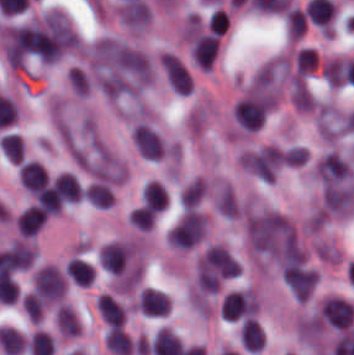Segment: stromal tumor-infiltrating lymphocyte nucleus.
Here are the masks:
<instances>
[{
  "label": "stromal tumor-infiltrating lymphocyte nucleus",
  "instance_id": "4c9ddf68",
  "mask_svg": "<svg viewBox=\"0 0 354 355\" xmlns=\"http://www.w3.org/2000/svg\"><path fill=\"white\" fill-rule=\"evenodd\" d=\"M65 273L71 282L76 285L85 287L91 282L93 278L91 267L86 262L74 257L66 262Z\"/></svg>",
  "mask_w": 354,
  "mask_h": 355
},
{
  "label": "stromal tumor-infiltrating lymphocyte nucleus",
  "instance_id": "42bb06b2",
  "mask_svg": "<svg viewBox=\"0 0 354 355\" xmlns=\"http://www.w3.org/2000/svg\"><path fill=\"white\" fill-rule=\"evenodd\" d=\"M88 202L97 208H107L112 197L106 186L98 183H91L85 193H84Z\"/></svg>",
  "mask_w": 354,
  "mask_h": 355
},
{
  "label": "stromal tumor-infiltrating lymphocyte nucleus",
  "instance_id": "2761f720",
  "mask_svg": "<svg viewBox=\"0 0 354 355\" xmlns=\"http://www.w3.org/2000/svg\"><path fill=\"white\" fill-rule=\"evenodd\" d=\"M165 204L164 187L155 181H148L143 188V205L159 211L164 209Z\"/></svg>",
  "mask_w": 354,
  "mask_h": 355
},
{
  "label": "stromal tumor-infiltrating lymphocyte nucleus",
  "instance_id": "4f13568d",
  "mask_svg": "<svg viewBox=\"0 0 354 355\" xmlns=\"http://www.w3.org/2000/svg\"><path fill=\"white\" fill-rule=\"evenodd\" d=\"M18 178L31 193L48 179L43 167L37 161H23L18 171Z\"/></svg>",
  "mask_w": 354,
  "mask_h": 355
},
{
  "label": "stromal tumor-infiltrating lymphocyte nucleus",
  "instance_id": "52c7bb5b",
  "mask_svg": "<svg viewBox=\"0 0 354 355\" xmlns=\"http://www.w3.org/2000/svg\"><path fill=\"white\" fill-rule=\"evenodd\" d=\"M130 247L125 244L108 242L97 255L98 266L107 273H120L128 257Z\"/></svg>",
  "mask_w": 354,
  "mask_h": 355
},
{
  "label": "stromal tumor-infiltrating lymphocyte nucleus",
  "instance_id": "4245b91a",
  "mask_svg": "<svg viewBox=\"0 0 354 355\" xmlns=\"http://www.w3.org/2000/svg\"><path fill=\"white\" fill-rule=\"evenodd\" d=\"M106 347L116 355H130L132 344L118 326H110L105 335Z\"/></svg>",
  "mask_w": 354,
  "mask_h": 355
},
{
  "label": "stromal tumor-infiltrating lymphocyte nucleus",
  "instance_id": "f3e2335f",
  "mask_svg": "<svg viewBox=\"0 0 354 355\" xmlns=\"http://www.w3.org/2000/svg\"><path fill=\"white\" fill-rule=\"evenodd\" d=\"M239 343L245 351H258L262 348V330L255 318L245 317L240 321Z\"/></svg>",
  "mask_w": 354,
  "mask_h": 355
},
{
  "label": "stromal tumor-infiltrating lymphocyte nucleus",
  "instance_id": "3c572f05",
  "mask_svg": "<svg viewBox=\"0 0 354 355\" xmlns=\"http://www.w3.org/2000/svg\"><path fill=\"white\" fill-rule=\"evenodd\" d=\"M1 151L11 162H20L23 154V140L14 133H7L0 143Z\"/></svg>",
  "mask_w": 354,
  "mask_h": 355
},
{
  "label": "stromal tumor-infiltrating lymphocyte nucleus",
  "instance_id": "bc302bb0",
  "mask_svg": "<svg viewBox=\"0 0 354 355\" xmlns=\"http://www.w3.org/2000/svg\"><path fill=\"white\" fill-rule=\"evenodd\" d=\"M267 97H248L235 104V123L248 130H256L265 120Z\"/></svg>",
  "mask_w": 354,
  "mask_h": 355
},
{
  "label": "stromal tumor-infiltrating lymphocyte nucleus",
  "instance_id": "9ea309e8",
  "mask_svg": "<svg viewBox=\"0 0 354 355\" xmlns=\"http://www.w3.org/2000/svg\"><path fill=\"white\" fill-rule=\"evenodd\" d=\"M138 310L148 315H164L170 306L165 293L151 288H144L139 292L137 300Z\"/></svg>",
  "mask_w": 354,
  "mask_h": 355
},
{
  "label": "stromal tumor-infiltrating lymphocyte nucleus",
  "instance_id": "9e4306bb",
  "mask_svg": "<svg viewBox=\"0 0 354 355\" xmlns=\"http://www.w3.org/2000/svg\"><path fill=\"white\" fill-rule=\"evenodd\" d=\"M21 304L27 316L31 320L38 322L41 311L43 309V304L38 296L35 293H28L22 297Z\"/></svg>",
  "mask_w": 354,
  "mask_h": 355
},
{
  "label": "stromal tumor-infiltrating lymphocyte nucleus",
  "instance_id": "04cf8593",
  "mask_svg": "<svg viewBox=\"0 0 354 355\" xmlns=\"http://www.w3.org/2000/svg\"><path fill=\"white\" fill-rule=\"evenodd\" d=\"M128 216L132 224L137 226L140 230H148L154 214L150 210L140 207L132 209Z\"/></svg>",
  "mask_w": 354,
  "mask_h": 355
},
{
  "label": "stromal tumor-infiltrating lymphocyte nucleus",
  "instance_id": "4803ca6d",
  "mask_svg": "<svg viewBox=\"0 0 354 355\" xmlns=\"http://www.w3.org/2000/svg\"><path fill=\"white\" fill-rule=\"evenodd\" d=\"M97 311L107 325H119L123 320V310L107 294H100L96 300Z\"/></svg>",
  "mask_w": 354,
  "mask_h": 355
},
{
  "label": "stromal tumor-infiltrating lymphocyte nucleus",
  "instance_id": "abfb95fc",
  "mask_svg": "<svg viewBox=\"0 0 354 355\" xmlns=\"http://www.w3.org/2000/svg\"><path fill=\"white\" fill-rule=\"evenodd\" d=\"M218 48V39L213 34L202 35L196 39L190 54L197 66L211 68Z\"/></svg>",
  "mask_w": 354,
  "mask_h": 355
},
{
  "label": "stromal tumor-infiltrating lymphocyte nucleus",
  "instance_id": "2a367800",
  "mask_svg": "<svg viewBox=\"0 0 354 355\" xmlns=\"http://www.w3.org/2000/svg\"><path fill=\"white\" fill-rule=\"evenodd\" d=\"M45 213L37 206L30 205L17 215L16 226L21 235H34L44 222Z\"/></svg>",
  "mask_w": 354,
  "mask_h": 355
},
{
  "label": "stromal tumor-infiltrating lymphocyte nucleus",
  "instance_id": "3290ff9b",
  "mask_svg": "<svg viewBox=\"0 0 354 355\" xmlns=\"http://www.w3.org/2000/svg\"><path fill=\"white\" fill-rule=\"evenodd\" d=\"M132 141L145 160H157L161 157L160 140L148 125L138 124L132 131Z\"/></svg>",
  "mask_w": 354,
  "mask_h": 355
}]
</instances>
